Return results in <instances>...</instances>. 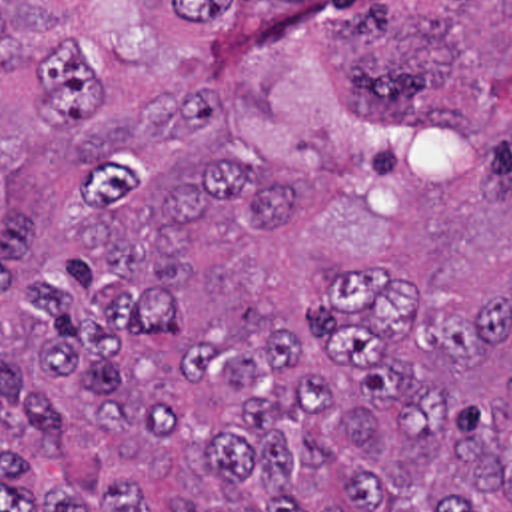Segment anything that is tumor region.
Returning a JSON list of instances; mask_svg holds the SVG:
<instances>
[{
    "mask_svg": "<svg viewBox=\"0 0 512 512\" xmlns=\"http://www.w3.org/2000/svg\"><path fill=\"white\" fill-rule=\"evenodd\" d=\"M0 0V512H512V0Z\"/></svg>",
    "mask_w": 512,
    "mask_h": 512,
    "instance_id": "obj_1",
    "label": "tumor region"
}]
</instances>
